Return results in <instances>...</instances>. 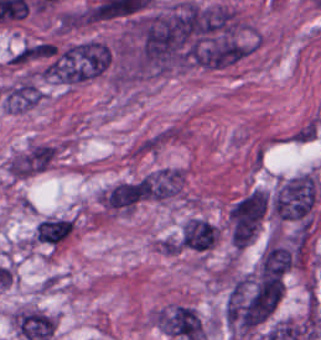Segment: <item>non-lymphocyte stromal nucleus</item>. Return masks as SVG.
<instances>
[{
	"mask_svg": "<svg viewBox=\"0 0 321 340\" xmlns=\"http://www.w3.org/2000/svg\"><path fill=\"white\" fill-rule=\"evenodd\" d=\"M216 239L214 226L203 218H190L182 226L181 247L206 250L213 247Z\"/></svg>",
	"mask_w": 321,
	"mask_h": 340,
	"instance_id": "7c5642bf",
	"label": "non-lymphocyte stromal nucleus"
},
{
	"mask_svg": "<svg viewBox=\"0 0 321 340\" xmlns=\"http://www.w3.org/2000/svg\"><path fill=\"white\" fill-rule=\"evenodd\" d=\"M162 326L166 332L201 338V321L194 310L189 307L175 305L164 316Z\"/></svg>",
	"mask_w": 321,
	"mask_h": 340,
	"instance_id": "81446118",
	"label": "non-lymphocyte stromal nucleus"
},
{
	"mask_svg": "<svg viewBox=\"0 0 321 340\" xmlns=\"http://www.w3.org/2000/svg\"><path fill=\"white\" fill-rule=\"evenodd\" d=\"M316 187L311 172H304L280 183L270 203L273 216L279 220L303 218L313 205Z\"/></svg>",
	"mask_w": 321,
	"mask_h": 340,
	"instance_id": "a72fc3eb",
	"label": "non-lymphocyte stromal nucleus"
},
{
	"mask_svg": "<svg viewBox=\"0 0 321 340\" xmlns=\"http://www.w3.org/2000/svg\"><path fill=\"white\" fill-rule=\"evenodd\" d=\"M290 265V249L269 238L258 260V274L264 278L289 270Z\"/></svg>",
	"mask_w": 321,
	"mask_h": 340,
	"instance_id": "9d01c50a",
	"label": "non-lymphocyte stromal nucleus"
},
{
	"mask_svg": "<svg viewBox=\"0 0 321 340\" xmlns=\"http://www.w3.org/2000/svg\"><path fill=\"white\" fill-rule=\"evenodd\" d=\"M268 211L265 197L252 190L239 197L227 215V239L237 252L248 247Z\"/></svg>",
	"mask_w": 321,
	"mask_h": 340,
	"instance_id": "dd21d789",
	"label": "non-lymphocyte stromal nucleus"
},
{
	"mask_svg": "<svg viewBox=\"0 0 321 340\" xmlns=\"http://www.w3.org/2000/svg\"><path fill=\"white\" fill-rule=\"evenodd\" d=\"M146 185L143 177L116 182L103 192L104 207L110 211H130L143 197Z\"/></svg>",
	"mask_w": 321,
	"mask_h": 340,
	"instance_id": "3746e769",
	"label": "non-lymphocyte stromal nucleus"
},
{
	"mask_svg": "<svg viewBox=\"0 0 321 340\" xmlns=\"http://www.w3.org/2000/svg\"><path fill=\"white\" fill-rule=\"evenodd\" d=\"M12 325L26 340H49L53 335L51 316L32 309H19L12 314Z\"/></svg>",
	"mask_w": 321,
	"mask_h": 340,
	"instance_id": "fc2b8d12",
	"label": "non-lymphocyte stromal nucleus"
},
{
	"mask_svg": "<svg viewBox=\"0 0 321 340\" xmlns=\"http://www.w3.org/2000/svg\"><path fill=\"white\" fill-rule=\"evenodd\" d=\"M72 224L69 218H43L35 227V238L54 245L67 237Z\"/></svg>",
	"mask_w": 321,
	"mask_h": 340,
	"instance_id": "2ac0efb1",
	"label": "non-lymphocyte stromal nucleus"
}]
</instances>
